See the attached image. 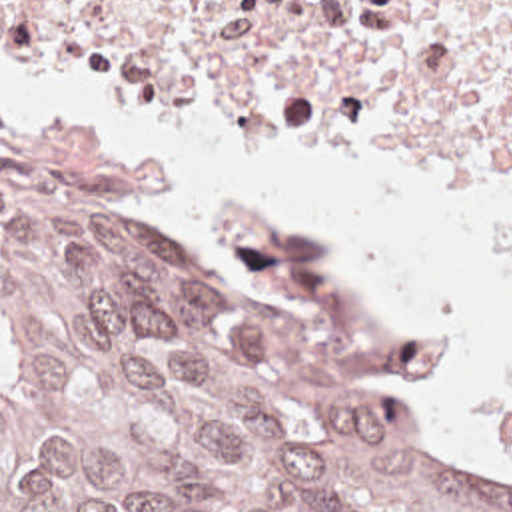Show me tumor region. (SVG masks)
<instances>
[{
  "label": "tumor region",
  "instance_id": "obj_1",
  "mask_svg": "<svg viewBox=\"0 0 512 512\" xmlns=\"http://www.w3.org/2000/svg\"><path fill=\"white\" fill-rule=\"evenodd\" d=\"M231 224L222 262L0 122V512H512L375 382L445 370L449 336L375 322L313 240Z\"/></svg>",
  "mask_w": 512,
  "mask_h": 512
}]
</instances>
